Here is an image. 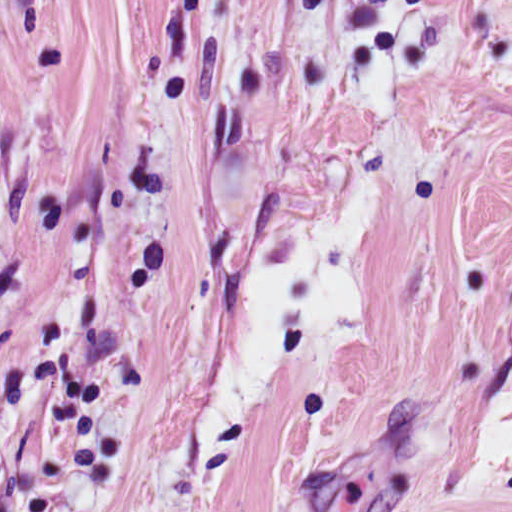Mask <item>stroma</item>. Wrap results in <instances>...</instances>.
Wrapping results in <instances>:
<instances>
[{
  "mask_svg": "<svg viewBox=\"0 0 512 512\" xmlns=\"http://www.w3.org/2000/svg\"><path fill=\"white\" fill-rule=\"evenodd\" d=\"M53 0H0V24Z\"/></svg>",
  "mask_w": 512,
  "mask_h": 512,
  "instance_id": "stroma-1",
  "label": "stroma"
}]
</instances>
